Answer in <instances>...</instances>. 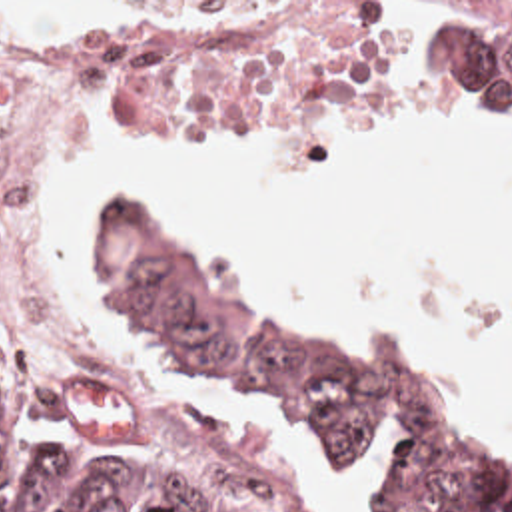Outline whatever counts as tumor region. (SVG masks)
<instances>
[{"label": "tumor region", "instance_id": "e687c5a6", "mask_svg": "<svg viewBox=\"0 0 512 512\" xmlns=\"http://www.w3.org/2000/svg\"><path fill=\"white\" fill-rule=\"evenodd\" d=\"M444 44L478 98L512 108V2H458L444 16ZM101 250L154 345L188 367L266 387L330 449L348 457L376 411L406 409L410 439L382 512H512V459L460 431L396 343L380 339L348 371L324 363L182 254L136 200L107 202ZM111 387L103 371H67L0 345V512H290L226 449L200 471H129L23 431L51 395Z\"/></svg>", "mask_w": 512, "mask_h": 512}]
</instances>
